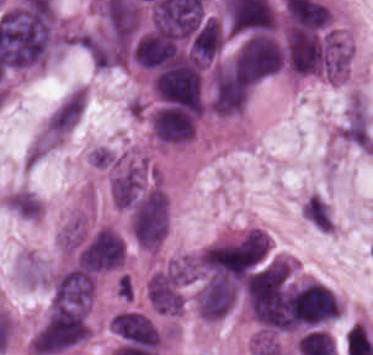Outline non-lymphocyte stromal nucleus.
Instances as JSON below:
<instances>
[{"mask_svg": "<svg viewBox=\"0 0 373 355\" xmlns=\"http://www.w3.org/2000/svg\"><path fill=\"white\" fill-rule=\"evenodd\" d=\"M85 107L83 86L69 90L48 113L44 124L46 142H59L77 123Z\"/></svg>", "mask_w": 373, "mask_h": 355, "instance_id": "obj_1", "label": "non-lymphocyte stromal nucleus"}, {"mask_svg": "<svg viewBox=\"0 0 373 355\" xmlns=\"http://www.w3.org/2000/svg\"><path fill=\"white\" fill-rule=\"evenodd\" d=\"M0 202L15 217L28 221L41 218L43 205L29 189L16 188L5 192Z\"/></svg>", "mask_w": 373, "mask_h": 355, "instance_id": "obj_2", "label": "non-lymphocyte stromal nucleus"}, {"mask_svg": "<svg viewBox=\"0 0 373 355\" xmlns=\"http://www.w3.org/2000/svg\"><path fill=\"white\" fill-rule=\"evenodd\" d=\"M14 270L23 284L37 287L48 285L47 264L30 250H23L16 255Z\"/></svg>", "mask_w": 373, "mask_h": 355, "instance_id": "obj_3", "label": "non-lymphocyte stromal nucleus"}]
</instances>
